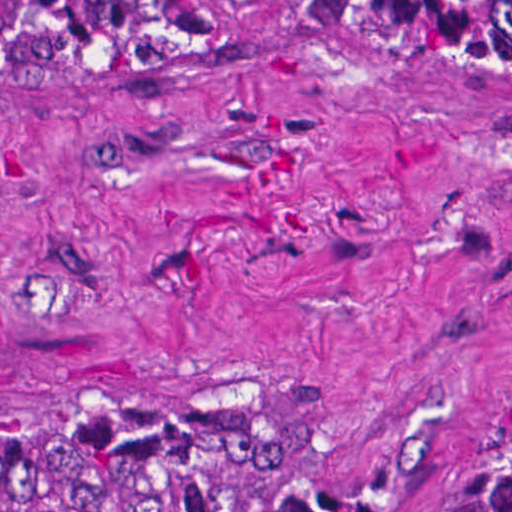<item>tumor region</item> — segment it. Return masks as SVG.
Returning a JSON list of instances; mask_svg holds the SVG:
<instances>
[{
  "label": "tumor region",
  "instance_id": "tumor-region-1",
  "mask_svg": "<svg viewBox=\"0 0 512 512\" xmlns=\"http://www.w3.org/2000/svg\"><path fill=\"white\" fill-rule=\"evenodd\" d=\"M133 58L177 54L184 8H233L423 47L451 76H512V0H51ZM282 391L127 377L1 421V512H254ZM398 512H512V413L425 444Z\"/></svg>",
  "mask_w": 512,
  "mask_h": 512
}]
</instances>
